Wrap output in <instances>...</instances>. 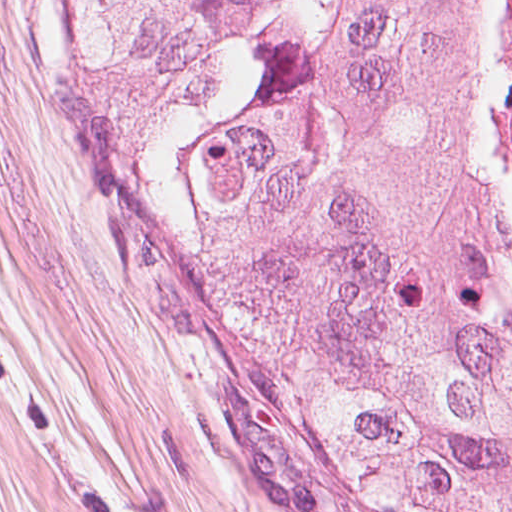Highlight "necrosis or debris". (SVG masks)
<instances>
[{
  "mask_svg": "<svg viewBox=\"0 0 512 512\" xmlns=\"http://www.w3.org/2000/svg\"><path fill=\"white\" fill-rule=\"evenodd\" d=\"M487 115L495 166L512 197V0H502L489 56Z\"/></svg>",
  "mask_w": 512,
  "mask_h": 512,
  "instance_id": "obj_1",
  "label": "necrosis or debris"
}]
</instances>
